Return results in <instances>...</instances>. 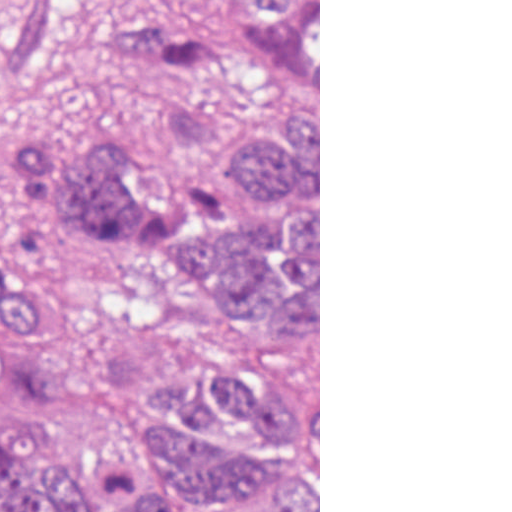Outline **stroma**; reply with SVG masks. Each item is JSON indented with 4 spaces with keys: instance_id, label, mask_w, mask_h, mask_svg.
Instances as JSON below:
<instances>
[{
    "instance_id": "stroma-1",
    "label": "stroma",
    "mask_w": 512,
    "mask_h": 512,
    "mask_svg": "<svg viewBox=\"0 0 512 512\" xmlns=\"http://www.w3.org/2000/svg\"><path fill=\"white\" fill-rule=\"evenodd\" d=\"M191 0H93L104 10H155ZM283 103L267 92L232 106L237 129ZM318 104V332L289 322L267 299H232L131 232L49 275L55 304L0 328V407L65 476L127 475L138 450L143 364L171 347H208L286 363L318 377L320 512V0ZM29 114L58 133L74 160L88 141L122 136L160 182L188 197L208 189L180 179L159 130L153 77L90 53L73 34L47 67ZM64 228V227H63ZM63 228L34 266L4 264L0 284L45 268ZM268 512V490L242 510Z\"/></svg>"
}]
</instances>
